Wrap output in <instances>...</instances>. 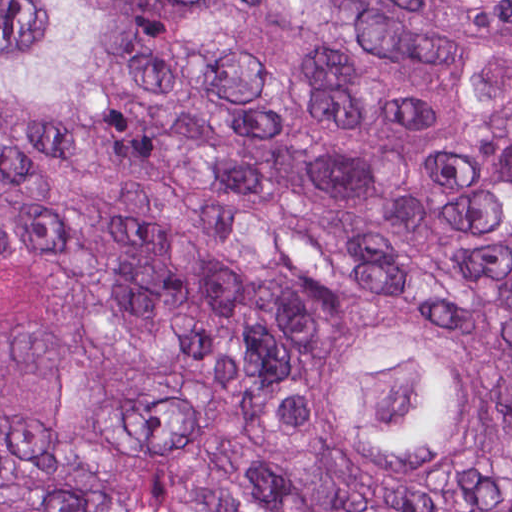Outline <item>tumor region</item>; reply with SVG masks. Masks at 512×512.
<instances>
[{"instance_id":"obj_1","label":"tumor region","mask_w":512,"mask_h":512,"mask_svg":"<svg viewBox=\"0 0 512 512\" xmlns=\"http://www.w3.org/2000/svg\"><path fill=\"white\" fill-rule=\"evenodd\" d=\"M512 86V0H446ZM137 41L120 139L0 118V245L70 242L66 390L0 406V512H512L502 450L445 493H378L292 437L277 355L353 308L449 328L512 307V126L454 45L360 0H107ZM92 0H0V89L113 100Z\"/></svg>"}]
</instances>
